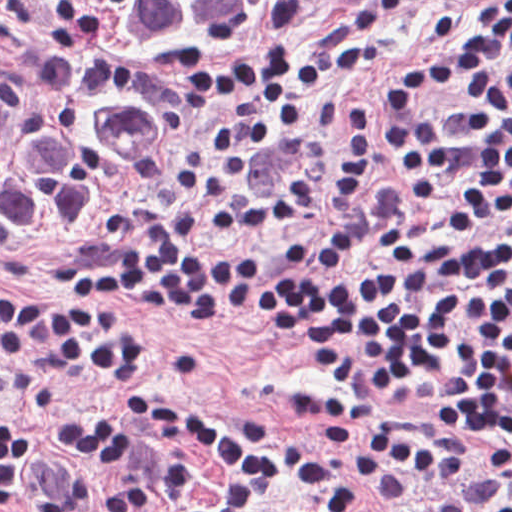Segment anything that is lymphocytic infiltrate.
Listing matches in <instances>:
<instances>
[{"label":"lymphocytic infiltrate","instance_id":"obj_1","mask_svg":"<svg viewBox=\"0 0 512 512\" xmlns=\"http://www.w3.org/2000/svg\"><path fill=\"white\" fill-rule=\"evenodd\" d=\"M415 1L367 0L313 55L261 53L208 83L202 94L216 127L187 145L170 187L179 235L142 221L108 271L58 290L0 287L1 367H90L161 441L143 449L121 423L78 421L63 429L65 446L137 467L173 490L192 485L189 457H203L215 467L213 494L170 500L125 476L71 473L23 423L0 415V512H271L287 497L308 512H356L363 497L352 470L386 504L405 501L401 467L447 485L466 477L458 448L390 420L370 428V404L345 392L312 407L325 444L363 438L344 461L323 445L287 441L254 412L218 417L145 391L159 353L129 307L264 319L359 393L436 379L457 396L464 431L512 440V231L377 280L304 276L279 259L202 245L280 233L355 200L375 146L372 114L359 101L348 103L328 154L268 193L249 187L251 151L298 144L311 126V92L367 68L387 20ZM434 35L440 53L393 72L378 135L392 182L433 236L448 237L512 210V0H487L469 28L434 12ZM488 512H512V500Z\"/></svg>","mask_w":512,"mask_h":512}]
</instances>
